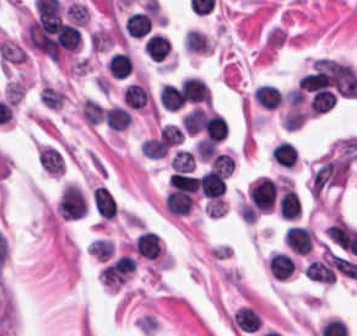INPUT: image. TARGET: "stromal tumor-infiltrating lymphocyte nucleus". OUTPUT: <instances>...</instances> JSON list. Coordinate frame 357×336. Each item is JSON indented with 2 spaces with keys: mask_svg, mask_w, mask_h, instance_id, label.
I'll list each match as a JSON object with an SVG mask.
<instances>
[{
  "mask_svg": "<svg viewBox=\"0 0 357 336\" xmlns=\"http://www.w3.org/2000/svg\"><path fill=\"white\" fill-rule=\"evenodd\" d=\"M87 213V201L74 184H67L59 199L58 215L64 220H78Z\"/></svg>",
  "mask_w": 357,
  "mask_h": 336,
  "instance_id": "obj_1",
  "label": "stromal tumor-infiltrating lymphocyte nucleus"
},
{
  "mask_svg": "<svg viewBox=\"0 0 357 336\" xmlns=\"http://www.w3.org/2000/svg\"><path fill=\"white\" fill-rule=\"evenodd\" d=\"M305 275L315 282L332 283L335 278V254L325 251L320 256L309 262Z\"/></svg>",
  "mask_w": 357,
  "mask_h": 336,
  "instance_id": "obj_2",
  "label": "stromal tumor-infiltrating lymphocyte nucleus"
},
{
  "mask_svg": "<svg viewBox=\"0 0 357 336\" xmlns=\"http://www.w3.org/2000/svg\"><path fill=\"white\" fill-rule=\"evenodd\" d=\"M180 94L186 104H209L207 85L202 77L188 76L181 80Z\"/></svg>",
  "mask_w": 357,
  "mask_h": 336,
  "instance_id": "obj_3",
  "label": "stromal tumor-infiltrating lymphocyte nucleus"
},
{
  "mask_svg": "<svg viewBox=\"0 0 357 336\" xmlns=\"http://www.w3.org/2000/svg\"><path fill=\"white\" fill-rule=\"evenodd\" d=\"M133 248L140 257L154 260L161 253L160 240L157 234L151 230H144L135 236Z\"/></svg>",
  "mask_w": 357,
  "mask_h": 336,
  "instance_id": "obj_4",
  "label": "stromal tumor-infiltrating lymphocyte nucleus"
},
{
  "mask_svg": "<svg viewBox=\"0 0 357 336\" xmlns=\"http://www.w3.org/2000/svg\"><path fill=\"white\" fill-rule=\"evenodd\" d=\"M284 241L290 251L305 255L312 247L311 230L302 227H289L285 230Z\"/></svg>",
  "mask_w": 357,
  "mask_h": 336,
  "instance_id": "obj_5",
  "label": "stromal tumor-infiltrating lymphocyte nucleus"
},
{
  "mask_svg": "<svg viewBox=\"0 0 357 336\" xmlns=\"http://www.w3.org/2000/svg\"><path fill=\"white\" fill-rule=\"evenodd\" d=\"M203 130L209 139L218 144L226 139L229 127L227 121L218 112L205 111Z\"/></svg>",
  "mask_w": 357,
  "mask_h": 336,
  "instance_id": "obj_6",
  "label": "stromal tumor-infiltrating lymphocyte nucleus"
},
{
  "mask_svg": "<svg viewBox=\"0 0 357 336\" xmlns=\"http://www.w3.org/2000/svg\"><path fill=\"white\" fill-rule=\"evenodd\" d=\"M203 197L207 199H219L226 191L225 177L214 171H206L198 179Z\"/></svg>",
  "mask_w": 357,
  "mask_h": 336,
  "instance_id": "obj_7",
  "label": "stromal tumor-infiltrating lymphocyte nucleus"
},
{
  "mask_svg": "<svg viewBox=\"0 0 357 336\" xmlns=\"http://www.w3.org/2000/svg\"><path fill=\"white\" fill-rule=\"evenodd\" d=\"M295 260L281 252L274 251L269 255L268 271L274 279H288L295 268Z\"/></svg>",
  "mask_w": 357,
  "mask_h": 336,
  "instance_id": "obj_8",
  "label": "stromal tumor-infiltrating lymphocyte nucleus"
},
{
  "mask_svg": "<svg viewBox=\"0 0 357 336\" xmlns=\"http://www.w3.org/2000/svg\"><path fill=\"white\" fill-rule=\"evenodd\" d=\"M92 205L100 218L112 219L116 215L117 206L110 193L102 187L92 190Z\"/></svg>",
  "mask_w": 357,
  "mask_h": 336,
  "instance_id": "obj_9",
  "label": "stromal tumor-infiltrating lymphocyte nucleus"
},
{
  "mask_svg": "<svg viewBox=\"0 0 357 336\" xmlns=\"http://www.w3.org/2000/svg\"><path fill=\"white\" fill-rule=\"evenodd\" d=\"M125 32L132 38H141L147 34L151 27L150 14L143 10H135L126 17L123 23Z\"/></svg>",
  "mask_w": 357,
  "mask_h": 336,
  "instance_id": "obj_10",
  "label": "stromal tumor-infiltrating lymphocyte nucleus"
},
{
  "mask_svg": "<svg viewBox=\"0 0 357 336\" xmlns=\"http://www.w3.org/2000/svg\"><path fill=\"white\" fill-rule=\"evenodd\" d=\"M37 160L47 174L62 175L63 157L59 149L42 146L38 152Z\"/></svg>",
  "mask_w": 357,
  "mask_h": 336,
  "instance_id": "obj_11",
  "label": "stromal tumor-infiltrating lymphocyte nucleus"
},
{
  "mask_svg": "<svg viewBox=\"0 0 357 336\" xmlns=\"http://www.w3.org/2000/svg\"><path fill=\"white\" fill-rule=\"evenodd\" d=\"M164 205L169 213L182 217L188 215L193 205V200L187 192L170 190L165 196Z\"/></svg>",
  "mask_w": 357,
  "mask_h": 336,
  "instance_id": "obj_12",
  "label": "stromal tumor-infiltrating lymphocyte nucleus"
},
{
  "mask_svg": "<svg viewBox=\"0 0 357 336\" xmlns=\"http://www.w3.org/2000/svg\"><path fill=\"white\" fill-rule=\"evenodd\" d=\"M253 97L264 110H274L281 101L278 88L268 83H261L253 92Z\"/></svg>",
  "mask_w": 357,
  "mask_h": 336,
  "instance_id": "obj_13",
  "label": "stromal tumor-infiltrating lymphocyte nucleus"
},
{
  "mask_svg": "<svg viewBox=\"0 0 357 336\" xmlns=\"http://www.w3.org/2000/svg\"><path fill=\"white\" fill-rule=\"evenodd\" d=\"M297 151L294 145L286 140L277 142L271 148V157L280 166L292 168L295 164Z\"/></svg>",
  "mask_w": 357,
  "mask_h": 336,
  "instance_id": "obj_14",
  "label": "stromal tumor-infiltrating lymphocyte nucleus"
},
{
  "mask_svg": "<svg viewBox=\"0 0 357 336\" xmlns=\"http://www.w3.org/2000/svg\"><path fill=\"white\" fill-rule=\"evenodd\" d=\"M105 123L115 131H123L128 127L132 117L129 111L120 105H113L104 111Z\"/></svg>",
  "mask_w": 357,
  "mask_h": 336,
  "instance_id": "obj_15",
  "label": "stromal tumor-infiltrating lymphocyte nucleus"
},
{
  "mask_svg": "<svg viewBox=\"0 0 357 336\" xmlns=\"http://www.w3.org/2000/svg\"><path fill=\"white\" fill-rule=\"evenodd\" d=\"M143 49L149 58L160 62L170 51V42L165 36L153 34L145 40Z\"/></svg>",
  "mask_w": 357,
  "mask_h": 336,
  "instance_id": "obj_16",
  "label": "stromal tumor-infiltrating lymphocyte nucleus"
},
{
  "mask_svg": "<svg viewBox=\"0 0 357 336\" xmlns=\"http://www.w3.org/2000/svg\"><path fill=\"white\" fill-rule=\"evenodd\" d=\"M279 214L283 218L294 219L301 210L299 196L289 188L284 189L278 202Z\"/></svg>",
  "mask_w": 357,
  "mask_h": 336,
  "instance_id": "obj_17",
  "label": "stromal tumor-infiltrating lymphocyte nucleus"
},
{
  "mask_svg": "<svg viewBox=\"0 0 357 336\" xmlns=\"http://www.w3.org/2000/svg\"><path fill=\"white\" fill-rule=\"evenodd\" d=\"M122 97L126 105L133 108H143L150 99L144 84L135 82L124 88Z\"/></svg>",
  "mask_w": 357,
  "mask_h": 336,
  "instance_id": "obj_18",
  "label": "stromal tumor-infiltrating lymphocyte nucleus"
},
{
  "mask_svg": "<svg viewBox=\"0 0 357 336\" xmlns=\"http://www.w3.org/2000/svg\"><path fill=\"white\" fill-rule=\"evenodd\" d=\"M106 68L108 73L117 78L128 77L132 70L130 56L123 51H116L111 56Z\"/></svg>",
  "mask_w": 357,
  "mask_h": 336,
  "instance_id": "obj_19",
  "label": "stromal tumor-infiltrating lymphocyte nucleus"
},
{
  "mask_svg": "<svg viewBox=\"0 0 357 336\" xmlns=\"http://www.w3.org/2000/svg\"><path fill=\"white\" fill-rule=\"evenodd\" d=\"M185 50L191 53H210L213 51L209 39L197 29L188 30L185 40Z\"/></svg>",
  "mask_w": 357,
  "mask_h": 336,
  "instance_id": "obj_20",
  "label": "stromal tumor-infiltrating lymphocyte nucleus"
},
{
  "mask_svg": "<svg viewBox=\"0 0 357 336\" xmlns=\"http://www.w3.org/2000/svg\"><path fill=\"white\" fill-rule=\"evenodd\" d=\"M160 106L170 110H178L182 107L181 98L178 89L175 85H161L158 94Z\"/></svg>",
  "mask_w": 357,
  "mask_h": 336,
  "instance_id": "obj_21",
  "label": "stromal tumor-infiltrating lymphocyte nucleus"
},
{
  "mask_svg": "<svg viewBox=\"0 0 357 336\" xmlns=\"http://www.w3.org/2000/svg\"><path fill=\"white\" fill-rule=\"evenodd\" d=\"M205 110L202 106H194L182 116L181 123L186 132L197 133L203 128Z\"/></svg>",
  "mask_w": 357,
  "mask_h": 336,
  "instance_id": "obj_22",
  "label": "stromal tumor-infiltrating lymphocyte nucleus"
},
{
  "mask_svg": "<svg viewBox=\"0 0 357 336\" xmlns=\"http://www.w3.org/2000/svg\"><path fill=\"white\" fill-rule=\"evenodd\" d=\"M169 181L172 190L194 194L199 188L197 176L172 173Z\"/></svg>",
  "mask_w": 357,
  "mask_h": 336,
  "instance_id": "obj_23",
  "label": "stromal tumor-infiltrating lymphocyte nucleus"
},
{
  "mask_svg": "<svg viewBox=\"0 0 357 336\" xmlns=\"http://www.w3.org/2000/svg\"><path fill=\"white\" fill-rule=\"evenodd\" d=\"M80 116L85 123H98L103 121L102 106L92 99H84L80 103Z\"/></svg>",
  "mask_w": 357,
  "mask_h": 336,
  "instance_id": "obj_24",
  "label": "stromal tumor-infiltrating lymphocyte nucleus"
},
{
  "mask_svg": "<svg viewBox=\"0 0 357 336\" xmlns=\"http://www.w3.org/2000/svg\"><path fill=\"white\" fill-rule=\"evenodd\" d=\"M170 166L176 172L189 173L194 170L195 157L192 152L184 149H177Z\"/></svg>",
  "mask_w": 357,
  "mask_h": 336,
  "instance_id": "obj_25",
  "label": "stromal tumor-infiltrating lymphocyte nucleus"
},
{
  "mask_svg": "<svg viewBox=\"0 0 357 336\" xmlns=\"http://www.w3.org/2000/svg\"><path fill=\"white\" fill-rule=\"evenodd\" d=\"M89 255L99 261H107L112 256L113 245L105 239L92 240L88 246Z\"/></svg>",
  "mask_w": 357,
  "mask_h": 336,
  "instance_id": "obj_26",
  "label": "stromal tumor-infiltrating lymphocyte nucleus"
},
{
  "mask_svg": "<svg viewBox=\"0 0 357 336\" xmlns=\"http://www.w3.org/2000/svg\"><path fill=\"white\" fill-rule=\"evenodd\" d=\"M233 157L231 154L219 153L210 160L209 170L224 176L230 175Z\"/></svg>",
  "mask_w": 357,
  "mask_h": 336,
  "instance_id": "obj_27",
  "label": "stromal tumor-infiltrating lymphocyte nucleus"
},
{
  "mask_svg": "<svg viewBox=\"0 0 357 336\" xmlns=\"http://www.w3.org/2000/svg\"><path fill=\"white\" fill-rule=\"evenodd\" d=\"M194 149L197 158L208 161L215 153L216 146L210 139L199 138L194 146Z\"/></svg>",
  "mask_w": 357,
  "mask_h": 336,
  "instance_id": "obj_28",
  "label": "stromal tumor-infiltrating lymphocyte nucleus"
}]
</instances>
